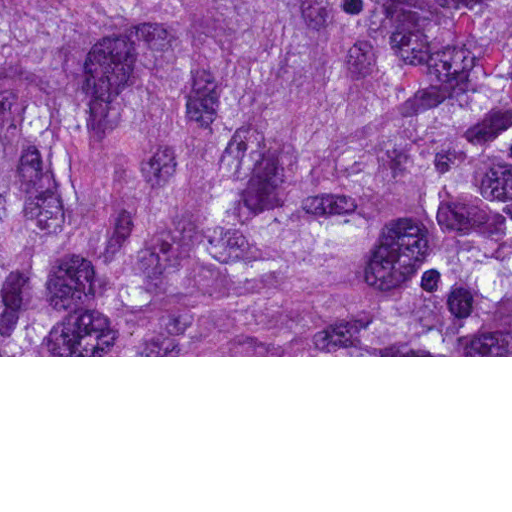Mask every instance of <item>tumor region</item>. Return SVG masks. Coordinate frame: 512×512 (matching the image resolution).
Returning <instances> with one entry per match:
<instances>
[{"mask_svg": "<svg viewBox=\"0 0 512 512\" xmlns=\"http://www.w3.org/2000/svg\"><path fill=\"white\" fill-rule=\"evenodd\" d=\"M0 356H512V0H0Z\"/></svg>", "mask_w": 512, "mask_h": 512, "instance_id": "e687c5a6", "label": "tumor region"}]
</instances>
